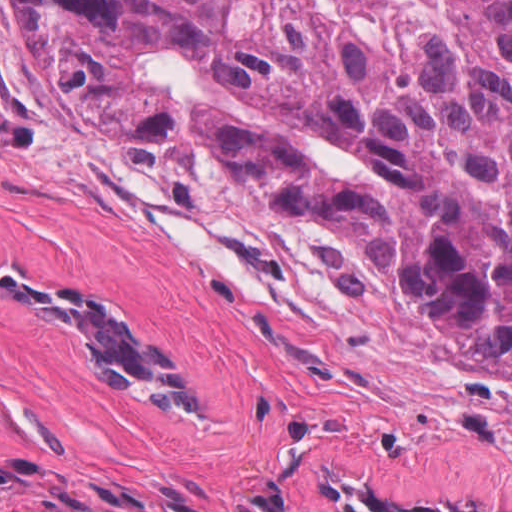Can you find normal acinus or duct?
<instances>
[{"instance_id":"obj_1","label":"normal acinus or duct","mask_w":512,"mask_h":512,"mask_svg":"<svg viewBox=\"0 0 512 512\" xmlns=\"http://www.w3.org/2000/svg\"><path fill=\"white\" fill-rule=\"evenodd\" d=\"M0 258V297L35 324L55 357L149 422L187 431L233 430L238 400L141 310L87 279ZM337 512H503L388 484L321 471Z\"/></svg>"}]
</instances>
